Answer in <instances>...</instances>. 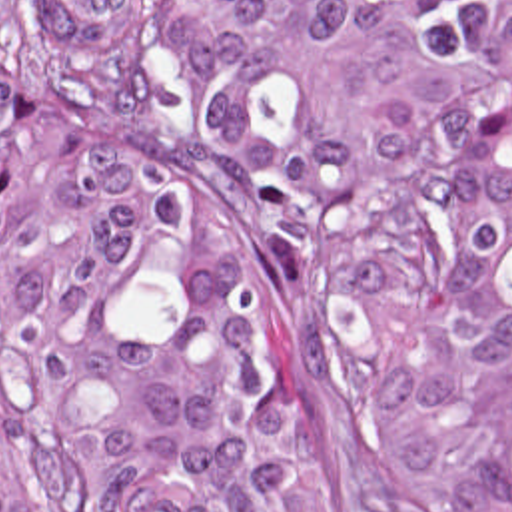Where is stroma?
<instances>
[{
  "label": "stroma",
  "mask_w": 512,
  "mask_h": 512,
  "mask_svg": "<svg viewBox=\"0 0 512 512\" xmlns=\"http://www.w3.org/2000/svg\"><path fill=\"white\" fill-rule=\"evenodd\" d=\"M131 107L217 202L249 250L261 286L289 320L323 400L337 474V512H418L389 450L383 400L349 374L337 344L333 280L287 238L267 187L225 163L191 127L181 93L175 0H145L131 65ZM0 474L11 512H65L51 472L0 396Z\"/></svg>",
  "instance_id": "stroma-1"
}]
</instances>
